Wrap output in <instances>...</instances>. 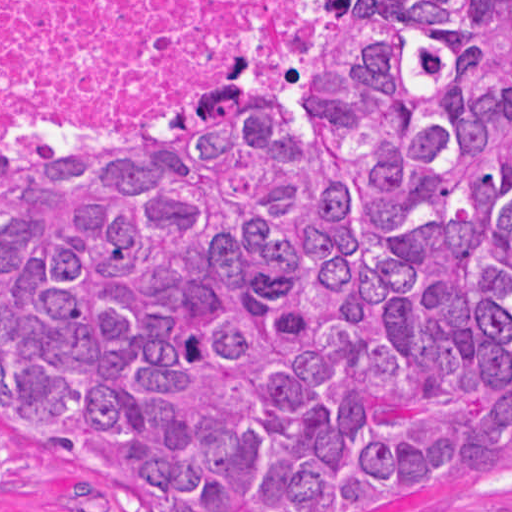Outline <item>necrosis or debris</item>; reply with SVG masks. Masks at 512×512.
<instances>
[{"label":"necrosis or debris","instance_id":"obj_1","mask_svg":"<svg viewBox=\"0 0 512 512\" xmlns=\"http://www.w3.org/2000/svg\"><path fill=\"white\" fill-rule=\"evenodd\" d=\"M373 0H0V173H85L259 109Z\"/></svg>","mask_w":512,"mask_h":512}]
</instances>
